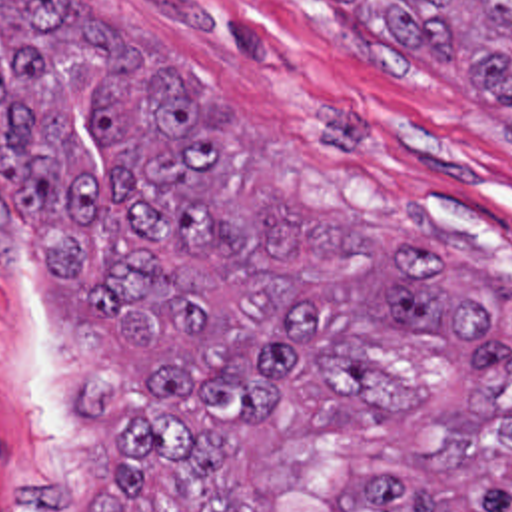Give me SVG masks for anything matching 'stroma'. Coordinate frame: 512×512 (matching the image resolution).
<instances>
[{"instance_id":"obj_1","label":"stroma","mask_w":512,"mask_h":512,"mask_svg":"<svg viewBox=\"0 0 512 512\" xmlns=\"http://www.w3.org/2000/svg\"><path fill=\"white\" fill-rule=\"evenodd\" d=\"M65 5L199 81L231 205L405 221L512 279V141L466 81L387 71L323 0ZM141 381L31 287L0 227V512H121Z\"/></svg>"}]
</instances>
